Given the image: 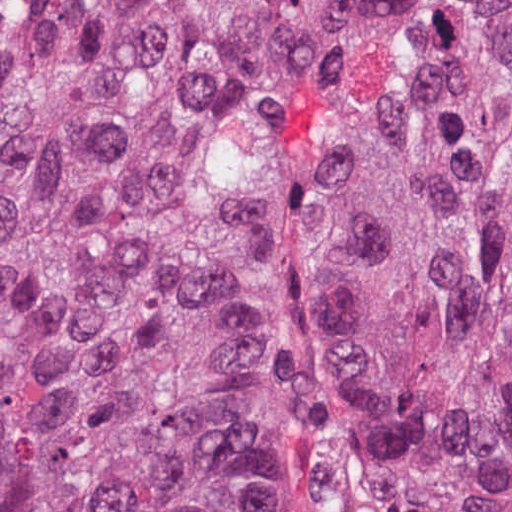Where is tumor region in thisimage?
<instances>
[{
    "label": "tumor region",
    "instance_id": "tumor-region-1",
    "mask_svg": "<svg viewBox=\"0 0 512 512\" xmlns=\"http://www.w3.org/2000/svg\"><path fill=\"white\" fill-rule=\"evenodd\" d=\"M0 512H512V0H0Z\"/></svg>",
    "mask_w": 512,
    "mask_h": 512
}]
</instances>
